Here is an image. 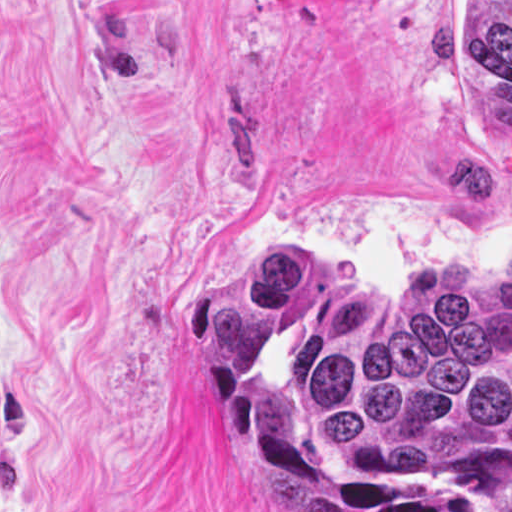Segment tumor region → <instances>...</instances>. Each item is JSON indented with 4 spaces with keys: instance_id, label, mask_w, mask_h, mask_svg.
Here are the masks:
<instances>
[{
    "instance_id": "e687c5a6",
    "label": "tumor region",
    "mask_w": 512,
    "mask_h": 512,
    "mask_svg": "<svg viewBox=\"0 0 512 512\" xmlns=\"http://www.w3.org/2000/svg\"><path fill=\"white\" fill-rule=\"evenodd\" d=\"M466 91L512 145V0H466ZM179 342L267 512H512V254L334 321L265 249L188 299Z\"/></svg>"
}]
</instances>
